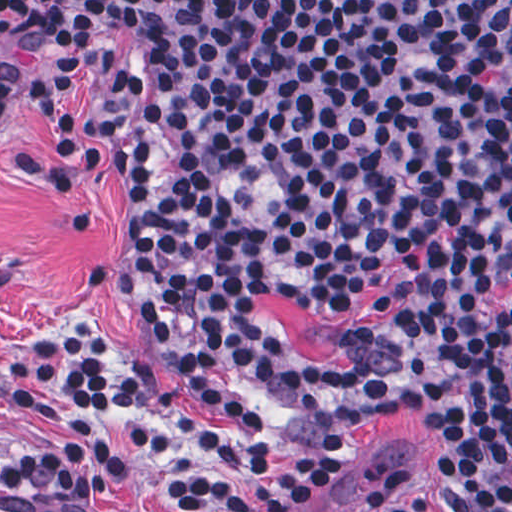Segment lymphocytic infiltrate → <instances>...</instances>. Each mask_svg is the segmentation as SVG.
Here are the masks:
<instances>
[{
    "label": "lymphocytic infiltrate",
    "mask_w": 512,
    "mask_h": 512,
    "mask_svg": "<svg viewBox=\"0 0 512 512\" xmlns=\"http://www.w3.org/2000/svg\"><path fill=\"white\" fill-rule=\"evenodd\" d=\"M113 77L128 142L114 262L200 402L285 429L392 394L512 319V0H0V122L33 98L50 156L3 165L63 209L75 167L68 88ZM374 321L316 364L257 306L266 293L343 313L381 276ZM445 512H512V386L488 364L417 388ZM0 403L61 411L0 489L70 512H138L111 486L109 411L153 458L200 472L150 484L154 512H311L352 468L231 436L180 412L156 356L123 364L86 314L0 355ZM353 512H433L380 472Z\"/></svg>",
    "instance_id": "lymphocytic-infiltrate-1"
}]
</instances>
